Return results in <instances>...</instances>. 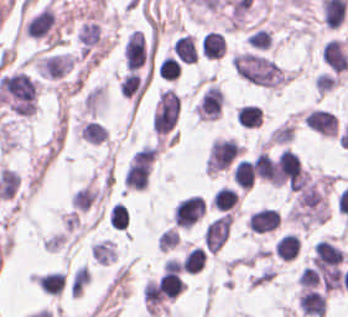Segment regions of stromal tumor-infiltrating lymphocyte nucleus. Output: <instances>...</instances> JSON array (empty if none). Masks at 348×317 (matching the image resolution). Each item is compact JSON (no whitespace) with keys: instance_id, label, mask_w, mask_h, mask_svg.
Instances as JSON below:
<instances>
[{"instance_id":"782c7336","label":"stromal tumor-infiltrating lymphocyte nucleus","mask_w":348,"mask_h":317,"mask_svg":"<svg viewBox=\"0 0 348 317\" xmlns=\"http://www.w3.org/2000/svg\"><path fill=\"white\" fill-rule=\"evenodd\" d=\"M128 208L121 203H114L111 206L109 223L112 228L126 229L128 224Z\"/></svg>"},{"instance_id":"4f13568d","label":"stromal tumor-infiltrating lymphocyte nucleus","mask_w":348,"mask_h":317,"mask_svg":"<svg viewBox=\"0 0 348 317\" xmlns=\"http://www.w3.org/2000/svg\"><path fill=\"white\" fill-rule=\"evenodd\" d=\"M54 22V12L50 6H43L28 21L26 30L28 36L38 37L48 32Z\"/></svg>"},{"instance_id":"3290ff9b","label":"stromal tumor-infiltrating lymphocyte nucleus","mask_w":348,"mask_h":317,"mask_svg":"<svg viewBox=\"0 0 348 317\" xmlns=\"http://www.w3.org/2000/svg\"><path fill=\"white\" fill-rule=\"evenodd\" d=\"M149 84V72L130 69L127 71L121 83L122 95L139 102Z\"/></svg>"},{"instance_id":"2a367800","label":"stromal tumor-infiltrating lymphocyte nucleus","mask_w":348,"mask_h":317,"mask_svg":"<svg viewBox=\"0 0 348 317\" xmlns=\"http://www.w3.org/2000/svg\"><path fill=\"white\" fill-rule=\"evenodd\" d=\"M174 54L183 62L195 63L198 54V47L194 36L191 33H184L173 43Z\"/></svg>"},{"instance_id":"abfb95fc","label":"stromal tumor-infiltrating lymphocyte nucleus","mask_w":348,"mask_h":317,"mask_svg":"<svg viewBox=\"0 0 348 317\" xmlns=\"http://www.w3.org/2000/svg\"><path fill=\"white\" fill-rule=\"evenodd\" d=\"M280 217L277 208L261 207L251 212L248 224L252 233H266L277 228Z\"/></svg>"},{"instance_id":"9e4306bb","label":"stromal tumor-infiltrating lymphocyte nucleus","mask_w":348,"mask_h":317,"mask_svg":"<svg viewBox=\"0 0 348 317\" xmlns=\"http://www.w3.org/2000/svg\"><path fill=\"white\" fill-rule=\"evenodd\" d=\"M181 65V62L167 54L158 64L157 74L162 79L175 80L180 73Z\"/></svg>"},{"instance_id":"2761f720","label":"stromal tumor-infiltrating lymphocyte nucleus","mask_w":348,"mask_h":317,"mask_svg":"<svg viewBox=\"0 0 348 317\" xmlns=\"http://www.w3.org/2000/svg\"><path fill=\"white\" fill-rule=\"evenodd\" d=\"M262 112L258 104L245 103L235 115L236 122L244 127L260 125Z\"/></svg>"},{"instance_id":"4c9ddf68","label":"stromal tumor-infiltrating lymphocyte nucleus","mask_w":348,"mask_h":317,"mask_svg":"<svg viewBox=\"0 0 348 317\" xmlns=\"http://www.w3.org/2000/svg\"><path fill=\"white\" fill-rule=\"evenodd\" d=\"M233 179L241 186L251 188L256 179L253 162L241 157L234 170Z\"/></svg>"},{"instance_id":"04cf8593","label":"stromal tumor-infiltrating lymphocyte nucleus","mask_w":348,"mask_h":317,"mask_svg":"<svg viewBox=\"0 0 348 317\" xmlns=\"http://www.w3.org/2000/svg\"><path fill=\"white\" fill-rule=\"evenodd\" d=\"M206 254L203 249L193 246L184 254L182 269L188 271H197L202 268Z\"/></svg>"},{"instance_id":"3c572f05","label":"stromal tumor-infiltrating lymphocyte nucleus","mask_w":348,"mask_h":317,"mask_svg":"<svg viewBox=\"0 0 348 317\" xmlns=\"http://www.w3.org/2000/svg\"><path fill=\"white\" fill-rule=\"evenodd\" d=\"M38 282L42 290L48 291L52 294H60L64 284V273L58 270H50L37 276Z\"/></svg>"},{"instance_id":"e9af9c67","label":"stromal tumor-infiltrating lymphocyte nucleus","mask_w":348,"mask_h":317,"mask_svg":"<svg viewBox=\"0 0 348 317\" xmlns=\"http://www.w3.org/2000/svg\"><path fill=\"white\" fill-rule=\"evenodd\" d=\"M254 169L257 177L264 178L272 182L273 161L265 151H261L254 160Z\"/></svg>"},{"instance_id":"4803ca6d","label":"stromal tumor-infiltrating lymphocyte nucleus","mask_w":348,"mask_h":317,"mask_svg":"<svg viewBox=\"0 0 348 317\" xmlns=\"http://www.w3.org/2000/svg\"><path fill=\"white\" fill-rule=\"evenodd\" d=\"M300 244L301 241L297 233L285 232L276 239L274 248L281 258L289 260L298 254Z\"/></svg>"},{"instance_id":"9ea309e8","label":"stromal tumor-infiltrating lymphocyte nucleus","mask_w":348,"mask_h":317,"mask_svg":"<svg viewBox=\"0 0 348 317\" xmlns=\"http://www.w3.org/2000/svg\"><path fill=\"white\" fill-rule=\"evenodd\" d=\"M297 303L308 315L321 316L325 309V297L322 291L309 286H302Z\"/></svg>"},{"instance_id":"bc302bb0","label":"stromal tumor-infiltrating lymphocyte nucleus","mask_w":348,"mask_h":317,"mask_svg":"<svg viewBox=\"0 0 348 317\" xmlns=\"http://www.w3.org/2000/svg\"><path fill=\"white\" fill-rule=\"evenodd\" d=\"M124 54L128 68H138L147 60L144 32L132 30L125 41Z\"/></svg>"},{"instance_id":"4245b91a","label":"stromal tumor-infiltrating lymphocyte nucleus","mask_w":348,"mask_h":317,"mask_svg":"<svg viewBox=\"0 0 348 317\" xmlns=\"http://www.w3.org/2000/svg\"><path fill=\"white\" fill-rule=\"evenodd\" d=\"M225 52V35L209 30L204 37L203 54L209 58H220Z\"/></svg>"},{"instance_id":"52c7bb5b","label":"stromal tumor-infiltrating lymphocyte nucleus","mask_w":348,"mask_h":317,"mask_svg":"<svg viewBox=\"0 0 348 317\" xmlns=\"http://www.w3.org/2000/svg\"><path fill=\"white\" fill-rule=\"evenodd\" d=\"M306 122L324 135H337L338 116L332 110L314 107L305 114Z\"/></svg>"},{"instance_id":"42bb06b2","label":"stromal tumor-infiltrating lymphocyte nucleus","mask_w":348,"mask_h":317,"mask_svg":"<svg viewBox=\"0 0 348 317\" xmlns=\"http://www.w3.org/2000/svg\"><path fill=\"white\" fill-rule=\"evenodd\" d=\"M239 193L234 187L222 186L213 193L212 203L219 210H227L237 203Z\"/></svg>"},{"instance_id":"f3e2335f","label":"stromal tumor-infiltrating lymphocyte nucleus","mask_w":348,"mask_h":317,"mask_svg":"<svg viewBox=\"0 0 348 317\" xmlns=\"http://www.w3.org/2000/svg\"><path fill=\"white\" fill-rule=\"evenodd\" d=\"M323 59L334 70L344 71L348 68V53L338 38L326 42L322 52Z\"/></svg>"}]
</instances>
